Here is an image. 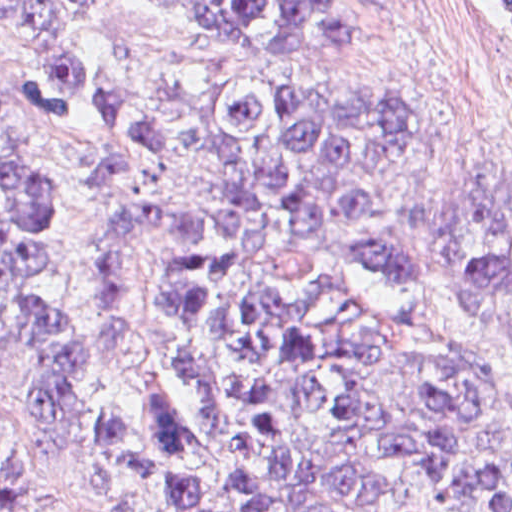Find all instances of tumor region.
Wrapping results in <instances>:
<instances>
[{"label":"tumor region","mask_w":512,"mask_h":512,"mask_svg":"<svg viewBox=\"0 0 512 512\" xmlns=\"http://www.w3.org/2000/svg\"><path fill=\"white\" fill-rule=\"evenodd\" d=\"M148 1L270 51L360 43L347 0ZM0 35L38 77L28 114L60 117L92 89L84 0H0ZM17 118L0 102V135ZM100 128L109 149L93 191L113 212L90 231L83 311L50 276L56 168L37 150L0 153V363L7 340L28 338L23 412L44 445L68 440L87 379L127 350L134 255L165 238L166 318L200 404L188 414L154 379L136 426L94 427L85 480L143 488L161 512H512V457L489 443L498 385L447 341L384 326L344 293L343 276L367 263L419 279L398 178L443 135L432 107L391 82H217L190 132L202 168L191 197L165 186L159 103L115 102ZM441 246L465 314H512V158L450 199ZM494 324L512 349V316ZM0 512H35L1 469Z\"/></svg>","instance_id":"1"}]
</instances>
